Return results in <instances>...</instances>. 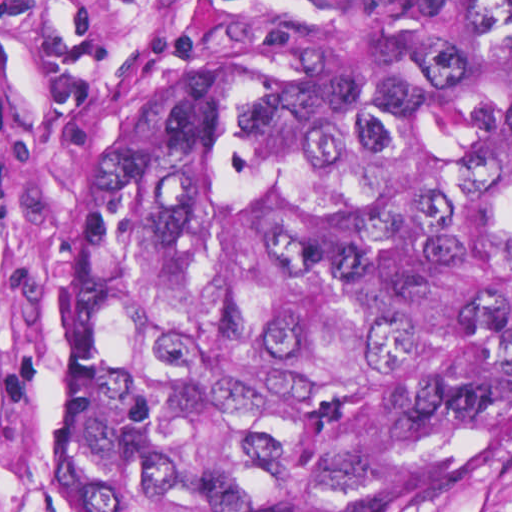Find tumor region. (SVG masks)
Masks as SVG:
<instances>
[{"label": "tumor region", "instance_id": "tumor-region-1", "mask_svg": "<svg viewBox=\"0 0 512 512\" xmlns=\"http://www.w3.org/2000/svg\"><path fill=\"white\" fill-rule=\"evenodd\" d=\"M200 1L66 226L74 512H392L512 318V0Z\"/></svg>", "mask_w": 512, "mask_h": 512}]
</instances>
